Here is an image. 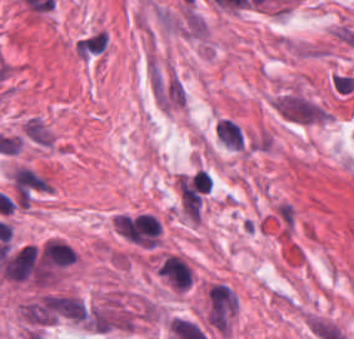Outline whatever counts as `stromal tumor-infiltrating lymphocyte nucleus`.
Here are the masks:
<instances>
[{"label":"stromal tumor-infiltrating lymphocyte nucleus","instance_id":"obj_2","mask_svg":"<svg viewBox=\"0 0 354 339\" xmlns=\"http://www.w3.org/2000/svg\"><path fill=\"white\" fill-rule=\"evenodd\" d=\"M218 143L228 149L242 150L245 135L237 122L227 116H220L213 128Z\"/></svg>","mask_w":354,"mask_h":339},{"label":"stromal tumor-infiltrating lymphocyte nucleus","instance_id":"obj_1","mask_svg":"<svg viewBox=\"0 0 354 339\" xmlns=\"http://www.w3.org/2000/svg\"><path fill=\"white\" fill-rule=\"evenodd\" d=\"M164 280L173 288L187 291L193 283V268L183 258L166 255L163 257Z\"/></svg>","mask_w":354,"mask_h":339}]
</instances>
